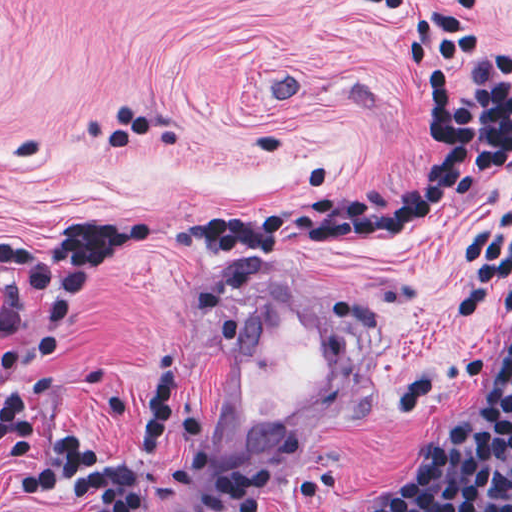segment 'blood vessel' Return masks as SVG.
<instances>
[{"mask_svg":"<svg viewBox=\"0 0 512 512\" xmlns=\"http://www.w3.org/2000/svg\"><path fill=\"white\" fill-rule=\"evenodd\" d=\"M369 352L345 312L284 269L243 299L200 421L224 465H262L359 399Z\"/></svg>","mask_w":512,"mask_h":512,"instance_id":"obj_1","label":"blood vessel"}]
</instances>
